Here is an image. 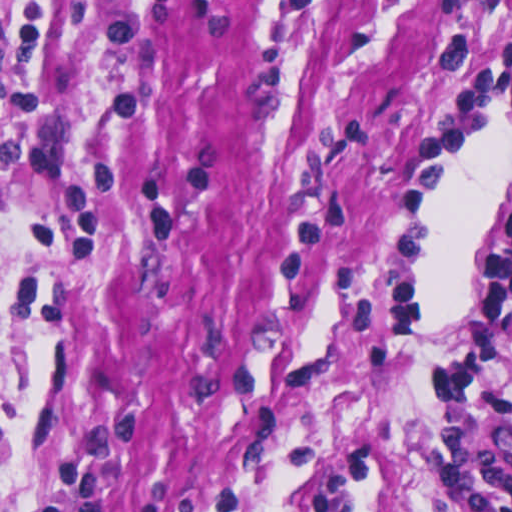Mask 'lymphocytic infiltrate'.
<instances>
[{"label": "lymphocytic infiltrate", "instance_id": "1", "mask_svg": "<svg viewBox=\"0 0 512 512\" xmlns=\"http://www.w3.org/2000/svg\"><path fill=\"white\" fill-rule=\"evenodd\" d=\"M327 0H257L281 37L313 33ZM406 487L427 512H512V211L441 343L403 441Z\"/></svg>", "mask_w": 512, "mask_h": 512}]
</instances>
